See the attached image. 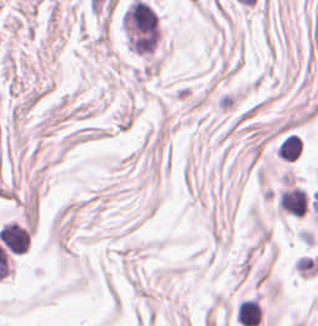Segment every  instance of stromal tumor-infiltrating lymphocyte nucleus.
I'll return each mask as SVG.
<instances>
[{
  "label": "stromal tumor-infiltrating lymphocyte nucleus",
  "instance_id": "1",
  "mask_svg": "<svg viewBox=\"0 0 318 326\" xmlns=\"http://www.w3.org/2000/svg\"><path fill=\"white\" fill-rule=\"evenodd\" d=\"M280 208L287 212L303 216L307 206V195L299 187L282 190L279 198Z\"/></svg>",
  "mask_w": 318,
  "mask_h": 326
},
{
  "label": "stromal tumor-infiltrating lymphocyte nucleus",
  "instance_id": "3",
  "mask_svg": "<svg viewBox=\"0 0 318 326\" xmlns=\"http://www.w3.org/2000/svg\"><path fill=\"white\" fill-rule=\"evenodd\" d=\"M302 149V136L295 132H290L281 141L280 156L288 159H297L301 154Z\"/></svg>",
  "mask_w": 318,
  "mask_h": 326
},
{
  "label": "stromal tumor-infiltrating lymphocyte nucleus",
  "instance_id": "2",
  "mask_svg": "<svg viewBox=\"0 0 318 326\" xmlns=\"http://www.w3.org/2000/svg\"><path fill=\"white\" fill-rule=\"evenodd\" d=\"M238 312L239 320L245 326H256L260 321L258 303L252 296L241 299Z\"/></svg>",
  "mask_w": 318,
  "mask_h": 326
}]
</instances>
